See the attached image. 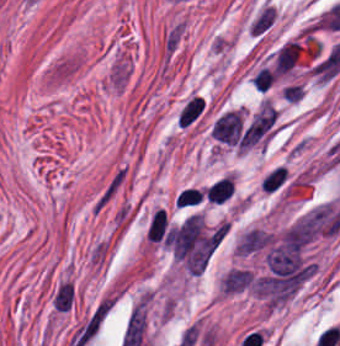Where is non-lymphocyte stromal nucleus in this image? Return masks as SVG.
Returning <instances> with one entry per match:
<instances>
[{
    "instance_id": "dd21d789",
    "label": "non-lymphocyte stromal nucleus",
    "mask_w": 340,
    "mask_h": 346,
    "mask_svg": "<svg viewBox=\"0 0 340 346\" xmlns=\"http://www.w3.org/2000/svg\"><path fill=\"white\" fill-rule=\"evenodd\" d=\"M276 20V9L268 0L249 18L247 32L254 38H262Z\"/></svg>"
},
{
    "instance_id": "a72fc3eb",
    "label": "non-lymphocyte stromal nucleus",
    "mask_w": 340,
    "mask_h": 346,
    "mask_svg": "<svg viewBox=\"0 0 340 346\" xmlns=\"http://www.w3.org/2000/svg\"><path fill=\"white\" fill-rule=\"evenodd\" d=\"M126 179L123 167H116L93 200L92 214H96L113 199Z\"/></svg>"
},
{
    "instance_id": "3746e769",
    "label": "non-lymphocyte stromal nucleus",
    "mask_w": 340,
    "mask_h": 346,
    "mask_svg": "<svg viewBox=\"0 0 340 346\" xmlns=\"http://www.w3.org/2000/svg\"><path fill=\"white\" fill-rule=\"evenodd\" d=\"M300 49L294 41H286L275 57L274 70L282 75L290 72L297 62Z\"/></svg>"
},
{
    "instance_id": "fc2b8d12",
    "label": "non-lymphocyte stromal nucleus",
    "mask_w": 340,
    "mask_h": 346,
    "mask_svg": "<svg viewBox=\"0 0 340 346\" xmlns=\"http://www.w3.org/2000/svg\"><path fill=\"white\" fill-rule=\"evenodd\" d=\"M184 36L183 21H175L163 34V58L164 61H170L178 50Z\"/></svg>"
},
{
    "instance_id": "81446118",
    "label": "non-lymphocyte stromal nucleus",
    "mask_w": 340,
    "mask_h": 346,
    "mask_svg": "<svg viewBox=\"0 0 340 346\" xmlns=\"http://www.w3.org/2000/svg\"><path fill=\"white\" fill-rule=\"evenodd\" d=\"M204 99L201 95H193L183 106L178 116V126H186L191 123L202 111Z\"/></svg>"
},
{
    "instance_id": "7c5642bf",
    "label": "non-lymphocyte stromal nucleus",
    "mask_w": 340,
    "mask_h": 346,
    "mask_svg": "<svg viewBox=\"0 0 340 346\" xmlns=\"http://www.w3.org/2000/svg\"><path fill=\"white\" fill-rule=\"evenodd\" d=\"M73 302V285L63 282L53 295V306L59 311H67Z\"/></svg>"
},
{
    "instance_id": "9d01c50a",
    "label": "non-lymphocyte stromal nucleus",
    "mask_w": 340,
    "mask_h": 346,
    "mask_svg": "<svg viewBox=\"0 0 340 346\" xmlns=\"http://www.w3.org/2000/svg\"><path fill=\"white\" fill-rule=\"evenodd\" d=\"M286 179V171L283 167H275L264 175L261 180L262 189L268 192L276 190Z\"/></svg>"
}]
</instances>
